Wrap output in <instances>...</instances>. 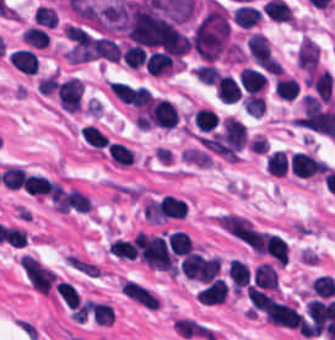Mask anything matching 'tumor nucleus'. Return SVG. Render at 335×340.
Instances as JSON below:
<instances>
[{"label": "tumor nucleus", "instance_id": "obj_1", "mask_svg": "<svg viewBox=\"0 0 335 340\" xmlns=\"http://www.w3.org/2000/svg\"><path fill=\"white\" fill-rule=\"evenodd\" d=\"M190 46L206 62H214L232 51L231 21L225 7L208 2L190 37Z\"/></svg>", "mask_w": 335, "mask_h": 340}]
</instances>
